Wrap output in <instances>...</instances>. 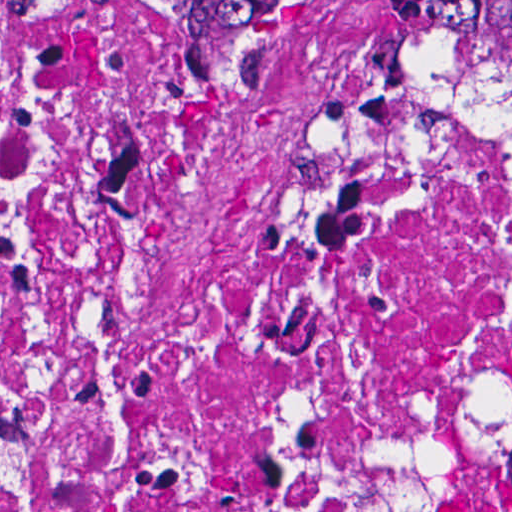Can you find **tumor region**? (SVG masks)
<instances>
[{
	"mask_svg": "<svg viewBox=\"0 0 512 512\" xmlns=\"http://www.w3.org/2000/svg\"><path fill=\"white\" fill-rule=\"evenodd\" d=\"M467 54L512 95V1H432Z\"/></svg>",
	"mask_w": 512,
	"mask_h": 512,
	"instance_id": "tumor-region-1",
	"label": "tumor region"
}]
</instances>
